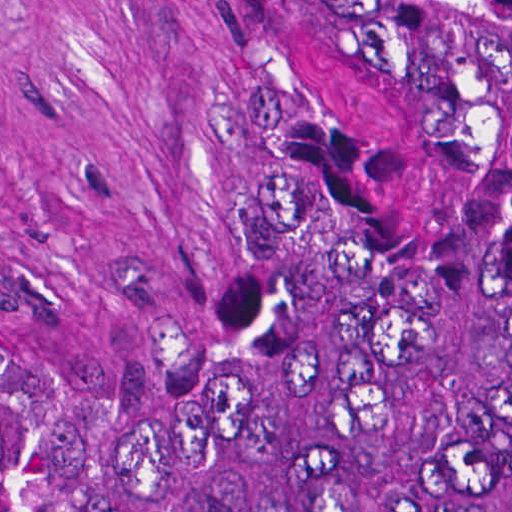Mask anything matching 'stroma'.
<instances>
[{
  "label": "stroma",
  "instance_id": "stroma-1",
  "mask_svg": "<svg viewBox=\"0 0 512 512\" xmlns=\"http://www.w3.org/2000/svg\"><path fill=\"white\" fill-rule=\"evenodd\" d=\"M229 168L230 0H0V305L169 335Z\"/></svg>",
  "mask_w": 512,
  "mask_h": 512
}]
</instances>
